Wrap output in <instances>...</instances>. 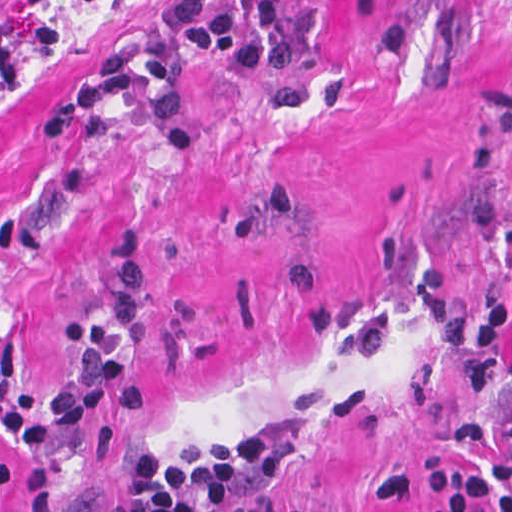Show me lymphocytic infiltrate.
Here are the masks:
<instances>
[{"instance_id": "1", "label": "lymphocytic infiltrate", "mask_w": 512, "mask_h": 512, "mask_svg": "<svg viewBox=\"0 0 512 512\" xmlns=\"http://www.w3.org/2000/svg\"><path fill=\"white\" fill-rule=\"evenodd\" d=\"M298 0H166L163 24L146 41L122 40L96 59L82 81L32 131L40 147L104 140L107 109L135 101L154 109L174 150L198 144L182 79L184 58L225 69L244 87L280 83L294 72ZM108 306L63 324L65 371L49 388L17 385L19 350L1 355V443L38 457L90 431L101 416L135 421L149 406L136 362L143 336L146 247L142 233H117ZM512 254V238L506 243ZM428 330L448 352H470L483 385H512V312L484 317L451 296L428 303ZM467 461L433 460L376 479V495H424L425 512H512L507 494L477 511L495 489L488 465L512 470V405L490 421L467 422L451 438ZM136 512H329L289 485L238 433L194 426L176 437L142 479Z\"/></svg>"}]
</instances>
